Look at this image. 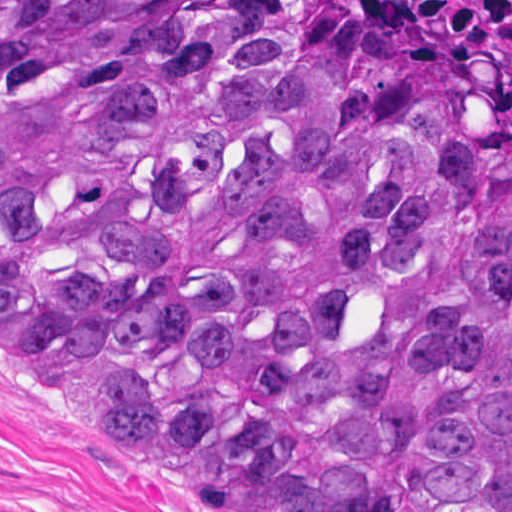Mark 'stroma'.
<instances>
[{"label":"stroma","mask_w":512,"mask_h":512,"mask_svg":"<svg viewBox=\"0 0 512 512\" xmlns=\"http://www.w3.org/2000/svg\"><path fill=\"white\" fill-rule=\"evenodd\" d=\"M0 512L240 511L191 467L0 357Z\"/></svg>","instance_id":"obj_1"}]
</instances>
